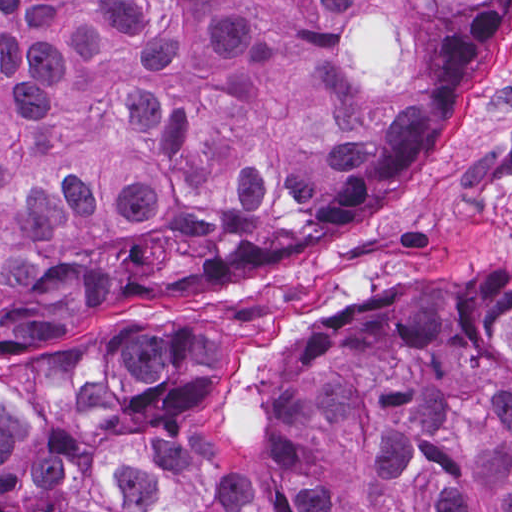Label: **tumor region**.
Here are the masks:
<instances>
[{
  "instance_id": "1",
  "label": "tumor region",
  "mask_w": 512,
  "mask_h": 512,
  "mask_svg": "<svg viewBox=\"0 0 512 512\" xmlns=\"http://www.w3.org/2000/svg\"><path fill=\"white\" fill-rule=\"evenodd\" d=\"M512 0H0V359L367 220ZM0 512H512V259L393 276L282 370L140 344L0 396Z\"/></svg>"
}]
</instances>
